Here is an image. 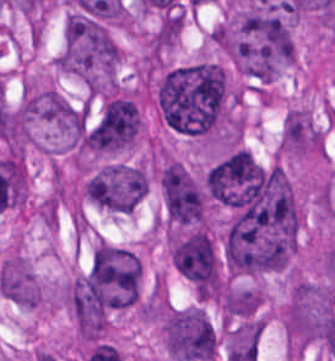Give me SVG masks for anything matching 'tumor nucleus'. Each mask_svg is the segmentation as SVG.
Returning <instances> with one entry per match:
<instances>
[{
    "label": "tumor nucleus",
    "instance_id": "1",
    "mask_svg": "<svg viewBox=\"0 0 335 361\" xmlns=\"http://www.w3.org/2000/svg\"><path fill=\"white\" fill-rule=\"evenodd\" d=\"M155 99L161 116L179 133H217L230 110L226 70L210 59L171 65L157 77Z\"/></svg>",
    "mask_w": 335,
    "mask_h": 361
},
{
    "label": "tumor nucleus",
    "instance_id": "2",
    "mask_svg": "<svg viewBox=\"0 0 335 361\" xmlns=\"http://www.w3.org/2000/svg\"><path fill=\"white\" fill-rule=\"evenodd\" d=\"M119 63L110 31L86 25L63 29L53 65L87 88H115Z\"/></svg>",
    "mask_w": 335,
    "mask_h": 361
},
{
    "label": "tumor nucleus",
    "instance_id": "3",
    "mask_svg": "<svg viewBox=\"0 0 335 361\" xmlns=\"http://www.w3.org/2000/svg\"><path fill=\"white\" fill-rule=\"evenodd\" d=\"M335 312V286L292 278L281 311L286 348L320 344Z\"/></svg>",
    "mask_w": 335,
    "mask_h": 361
},
{
    "label": "tumor nucleus",
    "instance_id": "4",
    "mask_svg": "<svg viewBox=\"0 0 335 361\" xmlns=\"http://www.w3.org/2000/svg\"><path fill=\"white\" fill-rule=\"evenodd\" d=\"M146 191V171L131 162L116 160L97 166L81 183L86 202L115 215H129Z\"/></svg>",
    "mask_w": 335,
    "mask_h": 361
},
{
    "label": "tumor nucleus",
    "instance_id": "5",
    "mask_svg": "<svg viewBox=\"0 0 335 361\" xmlns=\"http://www.w3.org/2000/svg\"><path fill=\"white\" fill-rule=\"evenodd\" d=\"M161 334L172 360H216L217 331L204 307H172L162 318Z\"/></svg>",
    "mask_w": 335,
    "mask_h": 361
},
{
    "label": "tumor nucleus",
    "instance_id": "6",
    "mask_svg": "<svg viewBox=\"0 0 335 361\" xmlns=\"http://www.w3.org/2000/svg\"><path fill=\"white\" fill-rule=\"evenodd\" d=\"M161 189L167 221L202 224L204 196L180 161L167 160L163 164Z\"/></svg>",
    "mask_w": 335,
    "mask_h": 361
},
{
    "label": "tumor nucleus",
    "instance_id": "7",
    "mask_svg": "<svg viewBox=\"0 0 335 361\" xmlns=\"http://www.w3.org/2000/svg\"><path fill=\"white\" fill-rule=\"evenodd\" d=\"M322 132L308 107L292 105L285 110L280 127L278 152L301 158L320 155Z\"/></svg>",
    "mask_w": 335,
    "mask_h": 361
},
{
    "label": "tumor nucleus",
    "instance_id": "8",
    "mask_svg": "<svg viewBox=\"0 0 335 361\" xmlns=\"http://www.w3.org/2000/svg\"><path fill=\"white\" fill-rule=\"evenodd\" d=\"M141 268L139 253L118 243L99 239L92 249L88 273L92 278L139 279Z\"/></svg>",
    "mask_w": 335,
    "mask_h": 361
}]
</instances>
